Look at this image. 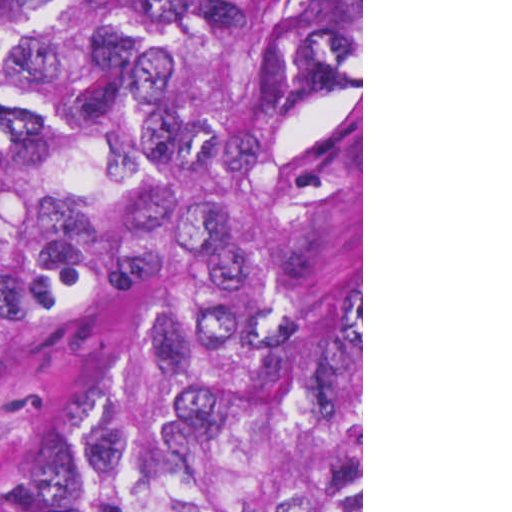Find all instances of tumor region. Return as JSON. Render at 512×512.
<instances>
[{"mask_svg":"<svg viewBox=\"0 0 512 512\" xmlns=\"http://www.w3.org/2000/svg\"><path fill=\"white\" fill-rule=\"evenodd\" d=\"M361 87V0H0V361L209 249L226 180ZM77 512H361V180L146 297L68 426Z\"/></svg>","mask_w":512,"mask_h":512,"instance_id":"obj_1","label":"tumor region"}]
</instances>
